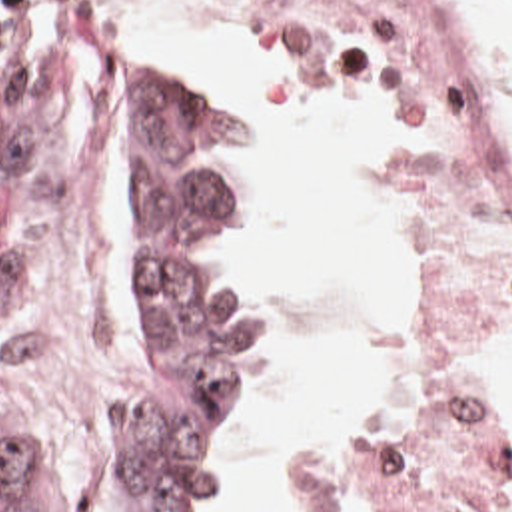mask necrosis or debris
<instances>
[{"label": "necrosis or debris", "instance_id": "1", "mask_svg": "<svg viewBox=\"0 0 512 512\" xmlns=\"http://www.w3.org/2000/svg\"><path fill=\"white\" fill-rule=\"evenodd\" d=\"M361 74L407 84L395 204V389L311 425L297 512H512V443L472 377L512 332V208L428 0H269Z\"/></svg>", "mask_w": 512, "mask_h": 512}]
</instances>
